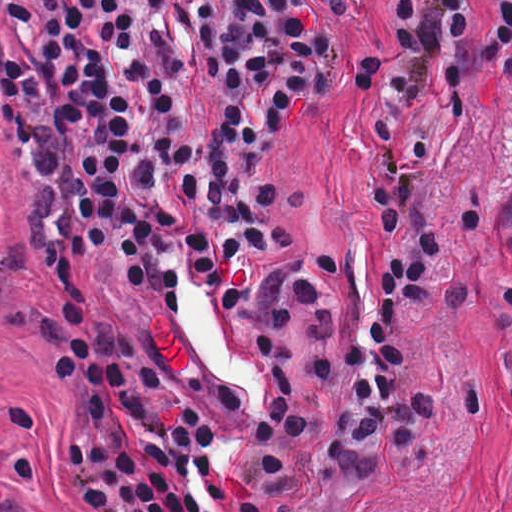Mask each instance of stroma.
Here are the masks:
<instances>
[{
    "label": "stroma",
    "mask_w": 512,
    "mask_h": 512,
    "mask_svg": "<svg viewBox=\"0 0 512 512\" xmlns=\"http://www.w3.org/2000/svg\"><path fill=\"white\" fill-rule=\"evenodd\" d=\"M487 40L502 32L501 0H475ZM313 21L333 41L330 69L318 90L285 124L279 146L254 173L280 200L285 244L258 255L262 274L284 258L309 262L325 298V321L338 342L334 373L316 382L312 331L291 321L292 372L315 407V430L290 461V494L271 512H512V92L495 96L512 60V40L480 74L472 101L430 107L403 138L387 108L369 111L359 90L361 64L400 43L393 0H306ZM166 31L190 71L183 133L206 138L204 120L218 105L216 88L196 66L173 10ZM439 111L442 145L422 174V191L451 194L431 221L394 236L378 228L380 127L398 153ZM476 194L492 201V219L468 234ZM30 166L0 104V502L5 512H78L82 486L65 447L64 410L46 345L55 324V294L31 228ZM438 235L444 265L428 312H417L415 345L430 377L485 386L492 402L482 421L449 412L439 461L423 468L391 451L376 483L345 482L325 449L348 394V345L369 323L377 261ZM85 297L95 314L134 333L160 380L152 399L174 414L178 399L198 406L214 430L213 467L238 497L248 488L241 469L250 430L228 409L208 362L214 338L200 322L168 304L136 295L115 252L93 251L81 264Z\"/></svg>",
    "instance_id": "stroma-1"
}]
</instances>
